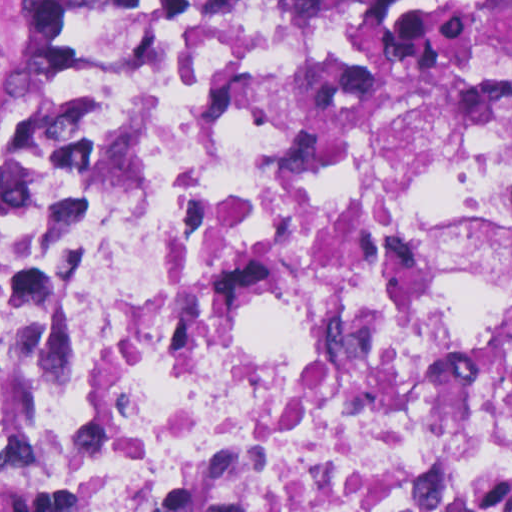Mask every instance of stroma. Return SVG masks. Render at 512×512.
I'll return each mask as SVG.
<instances>
[{"mask_svg": "<svg viewBox=\"0 0 512 512\" xmlns=\"http://www.w3.org/2000/svg\"><path fill=\"white\" fill-rule=\"evenodd\" d=\"M47 0H0V35L21 26Z\"/></svg>", "mask_w": 512, "mask_h": 512, "instance_id": "obj_1", "label": "stroma"}]
</instances>
